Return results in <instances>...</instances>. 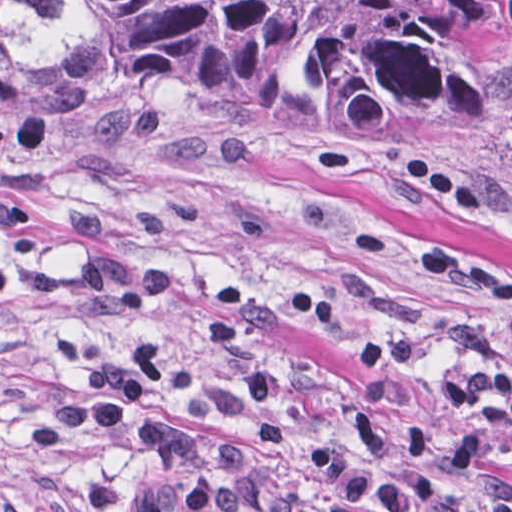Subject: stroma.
Returning <instances> with one entry per match:
<instances>
[{"label":"stroma","mask_w":512,"mask_h":512,"mask_svg":"<svg viewBox=\"0 0 512 512\" xmlns=\"http://www.w3.org/2000/svg\"><path fill=\"white\" fill-rule=\"evenodd\" d=\"M504 64L512 81V25ZM400 153L451 174L484 213L463 216L401 182ZM81 207L102 214L125 255L180 270V298L164 323L176 362L157 407L182 412L186 381L236 378L200 335L216 284L249 294L286 386L289 439L205 426L202 465L236 451L268 470L293 469L313 438L342 447L356 405L370 407L396 452L404 425L418 422L438 457L458 462L463 412L439 397L440 376L512 368V326L421 268V252L441 246L512 278V138L308 152L190 107L92 125L0 110V253L71 268L60 222ZM61 332L113 352L140 341L131 319L0 288V512H32L95 478L109 479L114 512H128L146 473L131 438L69 434L38 455L24 445L27 420L74 399L83 383L48 346ZM481 473L512 496L500 466Z\"/></svg>","instance_id":"1"}]
</instances>
